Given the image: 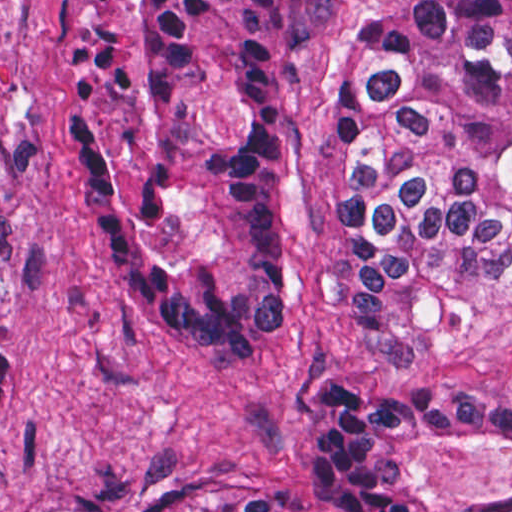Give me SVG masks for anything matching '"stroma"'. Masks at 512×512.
<instances>
[{
	"label": "stroma",
	"mask_w": 512,
	"mask_h": 512,
	"mask_svg": "<svg viewBox=\"0 0 512 512\" xmlns=\"http://www.w3.org/2000/svg\"><path fill=\"white\" fill-rule=\"evenodd\" d=\"M73 0H0V512H198L259 497L329 512L303 489L319 393L512 397L506 291L442 357L384 364L346 319L338 191L318 114L359 27L415 0H325L283 71V253L291 317L264 377L184 362L127 293L88 217L60 113V31ZM512 214V139L506 140ZM402 489L454 507H512V444L477 435L396 454Z\"/></svg>",
	"instance_id": "obj_1"
}]
</instances>
